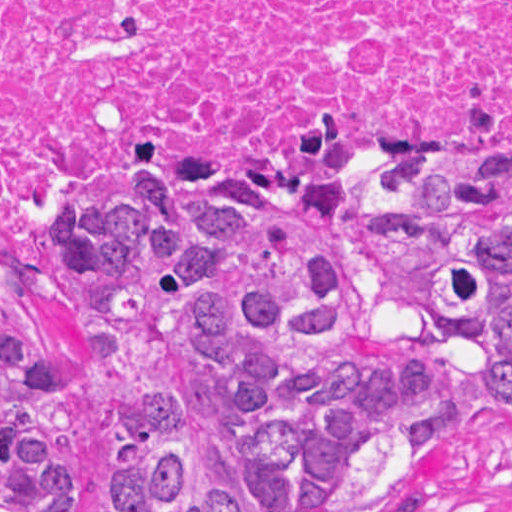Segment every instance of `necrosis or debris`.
Segmentation results:
<instances>
[{
	"label": "necrosis or debris",
	"instance_id": "4bbe7bcc",
	"mask_svg": "<svg viewBox=\"0 0 512 512\" xmlns=\"http://www.w3.org/2000/svg\"><path fill=\"white\" fill-rule=\"evenodd\" d=\"M186 173H512V0H0V278Z\"/></svg>",
	"mask_w": 512,
	"mask_h": 512
}]
</instances>
